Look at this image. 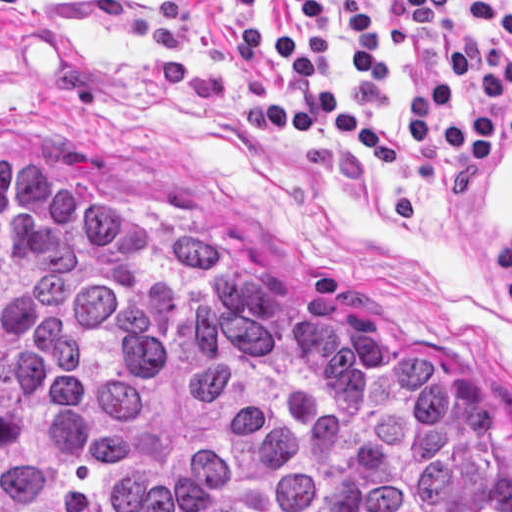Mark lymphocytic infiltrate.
Returning a JSON list of instances; mask_svg holds the SVG:
<instances>
[{"label":"lymphocytic infiltrate","mask_w":512,"mask_h":512,"mask_svg":"<svg viewBox=\"0 0 512 512\" xmlns=\"http://www.w3.org/2000/svg\"><path fill=\"white\" fill-rule=\"evenodd\" d=\"M15 0H0L1 5ZM300 20L284 34L259 17L234 39V62L248 72L267 57L277 59L299 97L261 111V123L283 138L299 139L317 123L345 140L367 148L376 162H400L402 141L393 131L354 115L335 98V42L324 0H297ZM449 0H392L389 32L414 59L407 92V125L418 144L451 165L491 168L498 147H512V58L491 41H472L454 54L451 65L485 93L486 105L455 108L454 90L429 78L424 54L405 36L440 32ZM482 29L512 39V9L500 0H454ZM350 24V56L355 97L364 111L376 113L383 103L377 60L381 39L365 0H342Z\"/></svg>","instance_id":"lymphocytic-infiltrate-1"}]
</instances>
